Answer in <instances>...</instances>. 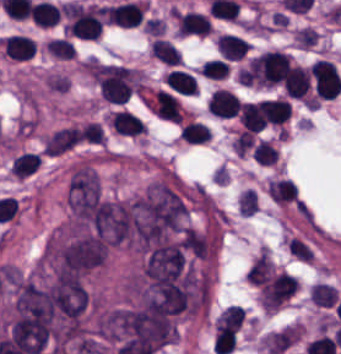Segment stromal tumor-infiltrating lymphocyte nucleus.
I'll use <instances>...</instances> for the list:
<instances>
[{
	"label": "stromal tumor-infiltrating lymphocyte nucleus",
	"instance_id": "stromal-tumor-infiltrating-lymphocyte-nucleus-6",
	"mask_svg": "<svg viewBox=\"0 0 341 354\" xmlns=\"http://www.w3.org/2000/svg\"><path fill=\"white\" fill-rule=\"evenodd\" d=\"M1 43L6 58L31 59L36 52V42L25 34L13 33L1 39Z\"/></svg>",
	"mask_w": 341,
	"mask_h": 354
},
{
	"label": "stromal tumor-infiltrating lymphocyte nucleus",
	"instance_id": "stromal-tumor-infiltrating-lymphocyte-nucleus-4",
	"mask_svg": "<svg viewBox=\"0 0 341 354\" xmlns=\"http://www.w3.org/2000/svg\"><path fill=\"white\" fill-rule=\"evenodd\" d=\"M176 30L183 36L210 33L213 26L207 15L197 11H176Z\"/></svg>",
	"mask_w": 341,
	"mask_h": 354
},
{
	"label": "stromal tumor-infiltrating lymphocyte nucleus",
	"instance_id": "stromal-tumor-infiltrating-lymphocyte-nucleus-10",
	"mask_svg": "<svg viewBox=\"0 0 341 354\" xmlns=\"http://www.w3.org/2000/svg\"><path fill=\"white\" fill-rule=\"evenodd\" d=\"M216 44L223 59L227 60H237L251 48L249 42L230 33H223L217 39Z\"/></svg>",
	"mask_w": 341,
	"mask_h": 354
},
{
	"label": "stromal tumor-infiltrating lymphocyte nucleus",
	"instance_id": "stromal-tumor-infiltrating-lymphocyte-nucleus-16",
	"mask_svg": "<svg viewBox=\"0 0 341 354\" xmlns=\"http://www.w3.org/2000/svg\"><path fill=\"white\" fill-rule=\"evenodd\" d=\"M45 46L56 59H74L75 57V48L69 39L51 38Z\"/></svg>",
	"mask_w": 341,
	"mask_h": 354
},
{
	"label": "stromal tumor-infiltrating lymphocyte nucleus",
	"instance_id": "stromal-tumor-infiltrating-lymphocyte-nucleus-7",
	"mask_svg": "<svg viewBox=\"0 0 341 354\" xmlns=\"http://www.w3.org/2000/svg\"><path fill=\"white\" fill-rule=\"evenodd\" d=\"M240 98L224 88H217L208 102V112L219 118H232L237 115Z\"/></svg>",
	"mask_w": 341,
	"mask_h": 354
},
{
	"label": "stromal tumor-infiltrating lymphocyte nucleus",
	"instance_id": "stromal-tumor-infiltrating-lymphocyte-nucleus-8",
	"mask_svg": "<svg viewBox=\"0 0 341 354\" xmlns=\"http://www.w3.org/2000/svg\"><path fill=\"white\" fill-rule=\"evenodd\" d=\"M109 124L115 131L126 135H139L147 131L144 120L128 109H115Z\"/></svg>",
	"mask_w": 341,
	"mask_h": 354
},
{
	"label": "stromal tumor-infiltrating lymphocyte nucleus",
	"instance_id": "stromal-tumor-infiltrating-lymphocyte-nucleus-15",
	"mask_svg": "<svg viewBox=\"0 0 341 354\" xmlns=\"http://www.w3.org/2000/svg\"><path fill=\"white\" fill-rule=\"evenodd\" d=\"M240 121L245 129L260 131L264 129L261 114L253 102H240Z\"/></svg>",
	"mask_w": 341,
	"mask_h": 354
},
{
	"label": "stromal tumor-infiltrating lymphocyte nucleus",
	"instance_id": "stromal-tumor-infiltrating-lymphocyte-nucleus-17",
	"mask_svg": "<svg viewBox=\"0 0 341 354\" xmlns=\"http://www.w3.org/2000/svg\"><path fill=\"white\" fill-rule=\"evenodd\" d=\"M204 77L225 78L229 73V64L223 59H209L202 66Z\"/></svg>",
	"mask_w": 341,
	"mask_h": 354
},
{
	"label": "stromal tumor-infiltrating lymphocyte nucleus",
	"instance_id": "stromal-tumor-infiltrating-lymphocyte-nucleus-14",
	"mask_svg": "<svg viewBox=\"0 0 341 354\" xmlns=\"http://www.w3.org/2000/svg\"><path fill=\"white\" fill-rule=\"evenodd\" d=\"M180 137L187 142L204 143L212 139V130L209 125L190 120L181 128Z\"/></svg>",
	"mask_w": 341,
	"mask_h": 354
},
{
	"label": "stromal tumor-infiltrating lymphocyte nucleus",
	"instance_id": "stromal-tumor-infiltrating-lymphocyte-nucleus-13",
	"mask_svg": "<svg viewBox=\"0 0 341 354\" xmlns=\"http://www.w3.org/2000/svg\"><path fill=\"white\" fill-rule=\"evenodd\" d=\"M152 51L154 58L168 65H180L181 52L169 39L158 37L152 43Z\"/></svg>",
	"mask_w": 341,
	"mask_h": 354
},
{
	"label": "stromal tumor-infiltrating lymphocyte nucleus",
	"instance_id": "stromal-tumor-infiltrating-lymphocyte-nucleus-9",
	"mask_svg": "<svg viewBox=\"0 0 341 354\" xmlns=\"http://www.w3.org/2000/svg\"><path fill=\"white\" fill-rule=\"evenodd\" d=\"M289 98L304 99L310 88L309 69L292 65L283 84Z\"/></svg>",
	"mask_w": 341,
	"mask_h": 354
},
{
	"label": "stromal tumor-infiltrating lymphocyte nucleus",
	"instance_id": "stromal-tumor-infiltrating-lymphocyte-nucleus-12",
	"mask_svg": "<svg viewBox=\"0 0 341 354\" xmlns=\"http://www.w3.org/2000/svg\"><path fill=\"white\" fill-rule=\"evenodd\" d=\"M31 11L36 26L50 27L59 19V6L51 1H37Z\"/></svg>",
	"mask_w": 341,
	"mask_h": 354
},
{
	"label": "stromal tumor-infiltrating lymphocyte nucleus",
	"instance_id": "stromal-tumor-infiltrating-lymphocyte-nucleus-5",
	"mask_svg": "<svg viewBox=\"0 0 341 354\" xmlns=\"http://www.w3.org/2000/svg\"><path fill=\"white\" fill-rule=\"evenodd\" d=\"M255 106L262 123L265 124L282 126L290 116L287 99H261Z\"/></svg>",
	"mask_w": 341,
	"mask_h": 354
},
{
	"label": "stromal tumor-infiltrating lymphocyte nucleus",
	"instance_id": "stromal-tumor-infiltrating-lymphocyte-nucleus-3",
	"mask_svg": "<svg viewBox=\"0 0 341 354\" xmlns=\"http://www.w3.org/2000/svg\"><path fill=\"white\" fill-rule=\"evenodd\" d=\"M147 105L155 115L181 123L182 116L178 98L166 89L157 88L150 96Z\"/></svg>",
	"mask_w": 341,
	"mask_h": 354
},
{
	"label": "stromal tumor-infiltrating lymphocyte nucleus",
	"instance_id": "stromal-tumor-infiltrating-lymphocyte-nucleus-2",
	"mask_svg": "<svg viewBox=\"0 0 341 354\" xmlns=\"http://www.w3.org/2000/svg\"><path fill=\"white\" fill-rule=\"evenodd\" d=\"M104 22L106 24L137 27L144 18V5L139 1H126L106 5L103 10Z\"/></svg>",
	"mask_w": 341,
	"mask_h": 354
},
{
	"label": "stromal tumor-infiltrating lymphocyte nucleus",
	"instance_id": "stromal-tumor-infiltrating-lymphocyte-nucleus-1",
	"mask_svg": "<svg viewBox=\"0 0 341 354\" xmlns=\"http://www.w3.org/2000/svg\"><path fill=\"white\" fill-rule=\"evenodd\" d=\"M309 73L317 98L333 99L341 89V77L333 63L317 59Z\"/></svg>",
	"mask_w": 341,
	"mask_h": 354
},
{
	"label": "stromal tumor-infiltrating lymphocyte nucleus",
	"instance_id": "stromal-tumor-infiltrating-lymphocyte-nucleus-11",
	"mask_svg": "<svg viewBox=\"0 0 341 354\" xmlns=\"http://www.w3.org/2000/svg\"><path fill=\"white\" fill-rule=\"evenodd\" d=\"M164 80L173 91L184 96H194L198 92L195 77L186 70L173 69L165 76Z\"/></svg>",
	"mask_w": 341,
	"mask_h": 354
}]
</instances>
